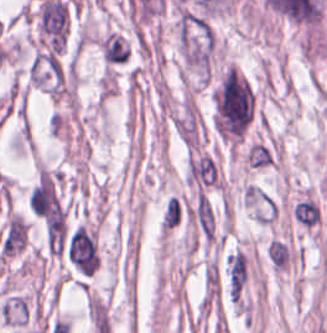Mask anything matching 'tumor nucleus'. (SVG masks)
Returning <instances> with one entry per match:
<instances>
[{"mask_svg": "<svg viewBox=\"0 0 327 333\" xmlns=\"http://www.w3.org/2000/svg\"><path fill=\"white\" fill-rule=\"evenodd\" d=\"M257 92L231 63L219 74L213 90L212 123L220 139L237 144L250 130Z\"/></svg>", "mask_w": 327, "mask_h": 333, "instance_id": "obj_1", "label": "tumor nucleus"}]
</instances>
